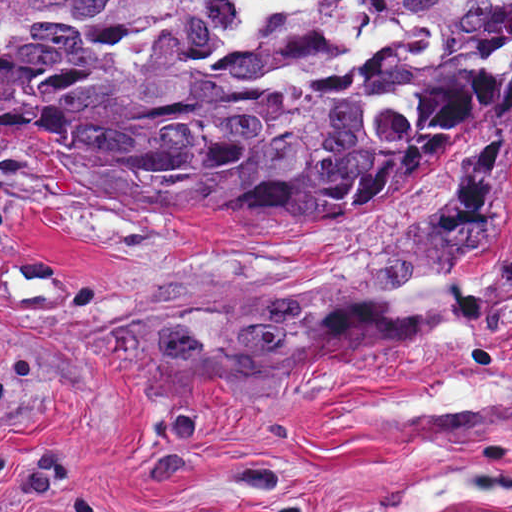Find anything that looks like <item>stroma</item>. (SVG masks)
<instances>
[{
  "label": "stroma",
  "instance_id": "1",
  "mask_svg": "<svg viewBox=\"0 0 512 512\" xmlns=\"http://www.w3.org/2000/svg\"><path fill=\"white\" fill-rule=\"evenodd\" d=\"M490 279L406 325L312 333L416 273ZM512 115L390 199L250 221L0 143V512H374L444 459L512 476ZM428 512H512V491Z\"/></svg>",
  "mask_w": 512,
  "mask_h": 512
}]
</instances>
